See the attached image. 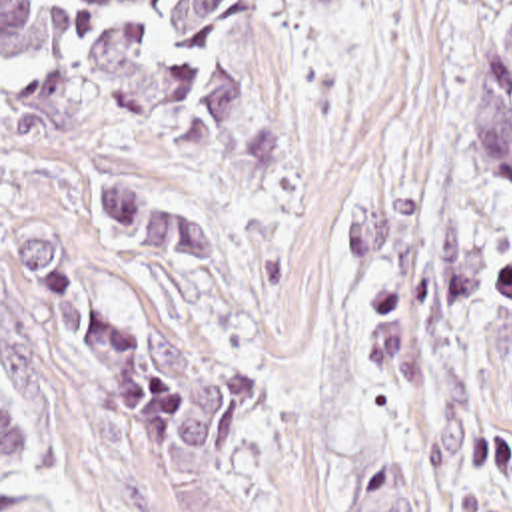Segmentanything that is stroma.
<instances>
[{"mask_svg":"<svg viewBox=\"0 0 512 512\" xmlns=\"http://www.w3.org/2000/svg\"><path fill=\"white\" fill-rule=\"evenodd\" d=\"M299 30L349 499L385 458L423 512H512V180L467 152L501 0H345ZM383 252L337 244L395 204ZM487 234L471 306L443 284L441 208Z\"/></svg>","mask_w":512,"mask_h":512,"instance_id":"35a3bbf8","label":"stroma"}]
</instances>
